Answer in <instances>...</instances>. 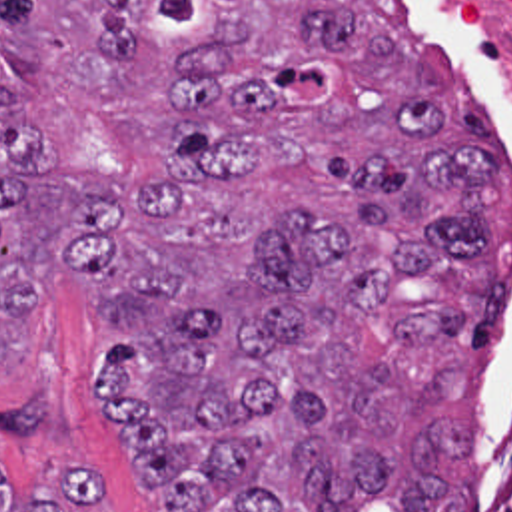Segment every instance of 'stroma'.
Returning a JSON list of instances; mask_svg holds the SVG:
<instances>
[{
	"mask_svg": "<svg viewBox=\"0 0 512 512\" xmlns=\"http://www.w3.org/2000/svg\"><path fill=\"white\" fill-rule=\"evenodd\" d=\"M406 1L424 59L471 113L499 127L505 153V185L487 227L489 269L501 277L499 317L491 335L463 345L465 400L477 424L481 456L512 362V107L457 0ZM110 353L92 277L52 281L22 360L0 370V462L18 478L16 502L46 494V482L58 474L98 468L106 476L110 512H154L102 412L100 382Z\"/></svg>",
	"mask_w": 512,
	"mask_h": 512,
	"instance_id": "1",
	"label": "stroma"
}]
</instances>
